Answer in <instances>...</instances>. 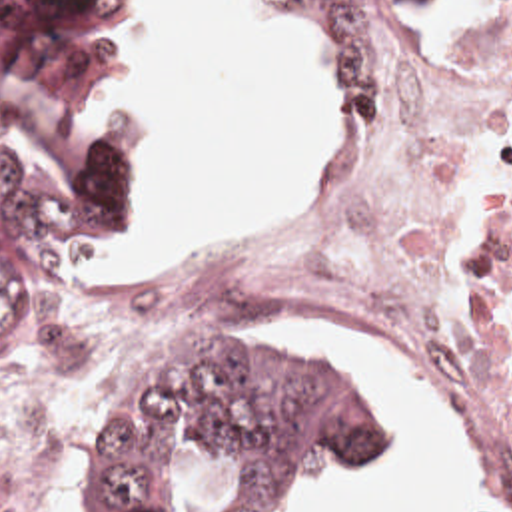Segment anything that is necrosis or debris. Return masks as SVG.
<instances>
[{"instance_id": "4bbe7bcc", "label": "necrosis or debris", "mask_w": 512, "mask_h": 512, "mask_svg": "<svg viewBox=\"0 0 512 512\" xmlns=\"http://www.w3.org/2000/svg\"><path fill=\"white\" fill-rule=\"evenodd\" d=\"M281 317H357L425 354L471 416L469 512H512V0L439 21L369 151L317 175L275 239L182 285L82 297L64 326L76 362H134ZM20 386L0 398V512H66L72 354Z\"/></svg>"}]
</instances>
